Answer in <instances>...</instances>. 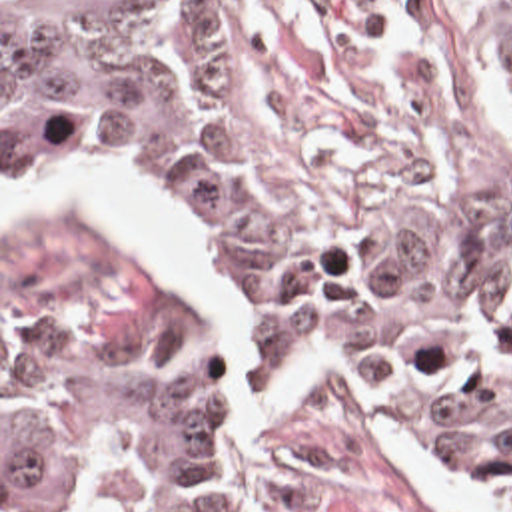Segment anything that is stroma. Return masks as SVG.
Instances as JSON below:
<instances>
[{
	"label": "stroma",
	"instance_id": "1",
	"mask_svg": "<svg viewBox=\"0 0 512 512\" xmlns=\"http://www.w3.org/2000/svg\"><path fill=\"white\" fill-rule=\"evenodd\" d=\"M226 90L238 164L294 248H397L473 214H512V0H190ZM114 172L164 212L180 242L174 274L70 206L2 218V178ZM126 278L178 290L208 354V390L252 482V512H447L383 454L351 382L335 374L306 408L242 436L226 406V352L256 392L304 358H331L381 404L399 442L449 480L512 512V491L479 476L429 432L377 372L335 348L226 344L192 238L152 174L92 154H2L0 0V512L2 316L44 312Z\"/></svg>",
	"mask_w": 512,
	"mask_h": 512
}]
</instances>
